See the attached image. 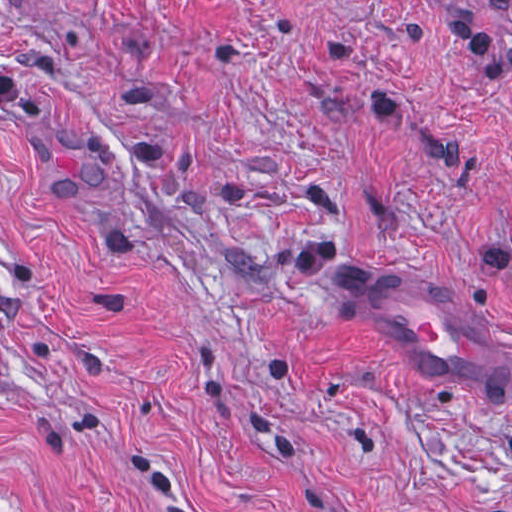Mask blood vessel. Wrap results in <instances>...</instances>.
Segmentation results:
<instances>
[{"label":"blood vessel","mask_w":512,"mask_h":512,"mask_svg":"<svg viewBox=\"0 0 512 512\" xmlns=\"http://www.w3.org/2000/svg\"><path fill=\"white\" fill-rule=\"evenodd\" d=\"M348 293L364 323L432 383L477 391L512 414V341L466 289L355 257Z\"/></svg>","instance_id":"obj_1"}]
</instances>
